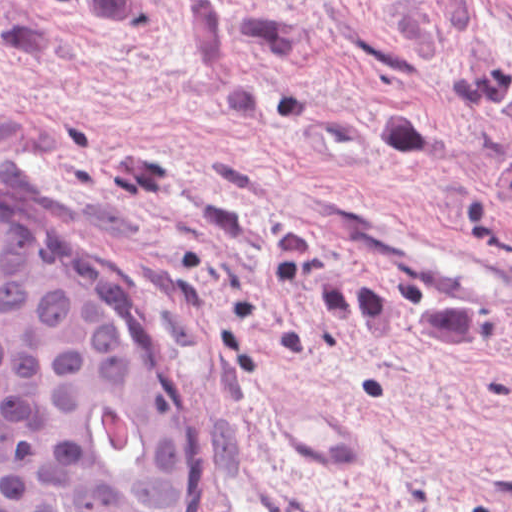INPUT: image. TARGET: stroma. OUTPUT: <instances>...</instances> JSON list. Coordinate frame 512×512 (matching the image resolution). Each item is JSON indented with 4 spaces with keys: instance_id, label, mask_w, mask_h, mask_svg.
Listing matches in <instances>:
<instances>
[{
    "instance_id": "obj_1",
    "label": "stroma",
    "mask_w": 512,
    "mask_h": 512,
    "mask_svg": "<svg viewBox=\"0 0 512 512\" xmlns=\"http://www.w3.org/2000/svg\"><path fill=\"white\" fill-rule=\"evenodd\" d=\"M393 102L414 168L367 147ZM341 191L512 264V0H0V205L76 238L177 359L182 512H512V296L292 195Z\"/></svg>"
}]
</instances>
